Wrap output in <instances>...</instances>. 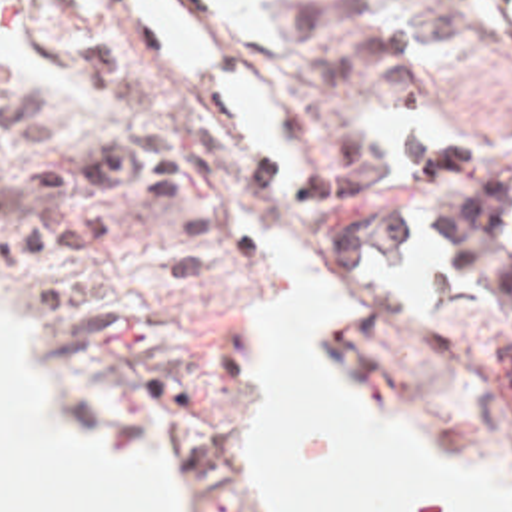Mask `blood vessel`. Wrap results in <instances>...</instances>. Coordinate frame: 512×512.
Listing matches in <instances>:
<instances>
[{
  "instance_id": "blood-vessel-1",
  "label": "blood vessel",
  "mask_w": 512,
  "mask_h": 512,
  "mask_svg": "<svg viewBox=\"0 0 512 512\" xmlns=\"http://www.w3.org/2000/svg\"><path fill=\"white\" fill-rule=\"evenodd\" d=\"M139 22L175 64L181 82L211 78L221 108L223 136L263 172L303 216L339 214V176L325 156L301 106L267 64L227 62L207 34L169 0H131Z\"/></svg>"
}]
</instances>
